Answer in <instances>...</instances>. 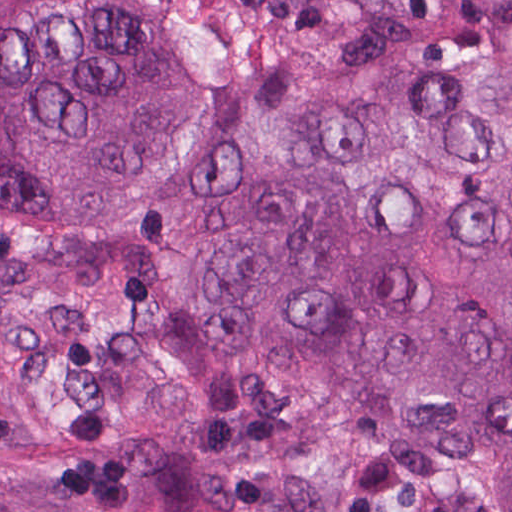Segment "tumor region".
Returning a JSON list of instances; mask_svg holds the SVG:
<instances>
[{"mask_svg": "<svg viewBox=\"0 0 512 512\" xmlns=\"http://www.w3.org/2000/svg\"><path fill=\"white\" fill-rule=\"evenodd\" d=\"M0 512H512V0H0Z\"/></svg>", "mask_w": 512, "mask_h": 512, "instance_id": "e687c5a6", "label": "tumor region"}]
</instances>
